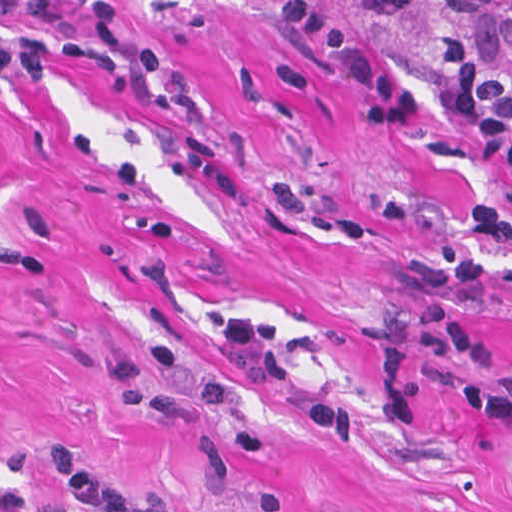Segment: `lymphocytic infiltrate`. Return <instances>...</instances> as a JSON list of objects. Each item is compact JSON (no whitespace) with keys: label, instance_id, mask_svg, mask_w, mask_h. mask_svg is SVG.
Listing matches in <instances>:
<instances>
[{"label":"lymphocytic infiltrate","instance_id":"1","mask_svg":"<svg viewBox=\"0 0 512 512\" xmlns=\"http://www.w3.org/2000/svg\"><path fill=\"white\" fill-rule=\"evenodd\" d=\"M437 69L460 105L466 125L512 183V0H422ZM369 18H398L420 0H349ZM0 11L45 26L34 30L0 18V75L41 79L62 60H89L112 71L129 64L139 99L158 108L187 105V85L155 47L128 41L108 0H92L93 27H64L43 0H0ZM284 22L310 56L347 77L360 96L358 117L371 128H415L422 123V94L395 75L364 42L310 0H287ZM512 239V207L498 195L467 202L453 240L411 265L415 307L406 322V349L435 348L452 360L473 362L478 379L445 382L449 399L492 427H512V367L464 315L478 296L481 264ZM222 356L235 372L269 385L291 379L288 356L273 321L250 313L224 320ZM48 477L68 485L72 512H172L104 490L75 454H43ZM256 512H284V494H264Z\"/></svg>","mask_w":512,"mask_h":512}]
</instances>
